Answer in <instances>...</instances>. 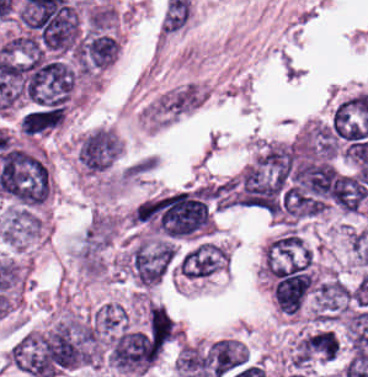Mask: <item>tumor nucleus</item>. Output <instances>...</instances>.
Here are the masks:
<instances>
[{
  "label": "tumor nucleus",
  "instance_id": "tumor-nucleus-1",
  "mask_svg": "<svg viewBox=\"0 0 368 377\" xmlns=\"http://www.w3.org/2000/svg\"><path fill=\"white\" fill-rule=\"evenodd\" d=\"M175 257V246L167 241L137 239L129 253V271L142 288L159 283Z\"/></svg>",
  "mask_w": 368,
  "mask_h": 377
},
{
  "label": "tumor nucleus",
  "instance_id": "tumor-nucleus-2",
  "mask_svg": "<svg viewBox=\"0 0 368 377\" xmlns=\"http://www.w3.org/2000/svg\"><path fill=\"white\" fill-rule=\"evenodd\" d=\"M228 262L222 246L207 240L194 242L177 259L174 277L182 282H204Z\"/></svg>",
  "mask_w": 368,
  "mask_h": 377
}]
</instances>
